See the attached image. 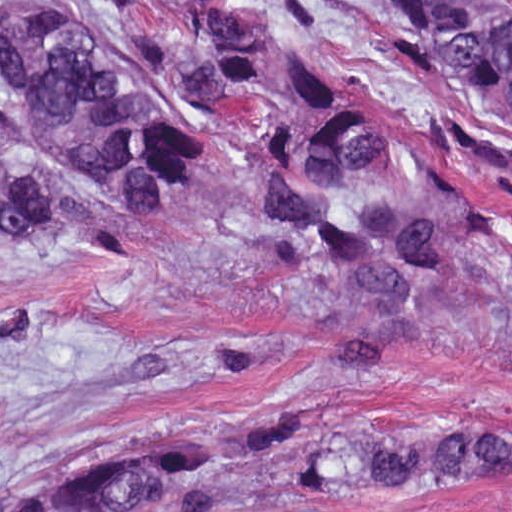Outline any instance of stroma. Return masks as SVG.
Returning <instances> with one entry per match:
<instances>
[{"label":"stroma","mask_w":512,"mask_h":512,"mask_svg":"<svg viewBox=\"0 0 512 512\" xmlns=\"http://www.w3.org/2000/svg\"><path fill=\"white\" fill-rule=\"evenodd\" d=\"M1 1H108L90 28L113 83L203 127V153L158 224L58 167L23 114L12 163L95 215L99 250L32 222L1 223ZM148 1H273L262 69L223 103L188 95L172 18ZM370 1L0 0L1 431L53 450L12 484L131 447L221 432L249 407L327 403L377 435L496 420L512 425V318L337 364L269 306L246 217L244 166L285 67L312 68L349 100L448 155L512 237V111L436 72ZM512 267V256L490 269ZM257 512H512V472L448 487L295 497Z\"/></svg>","instance_id":"35a3bbf8"}]
</instances>
